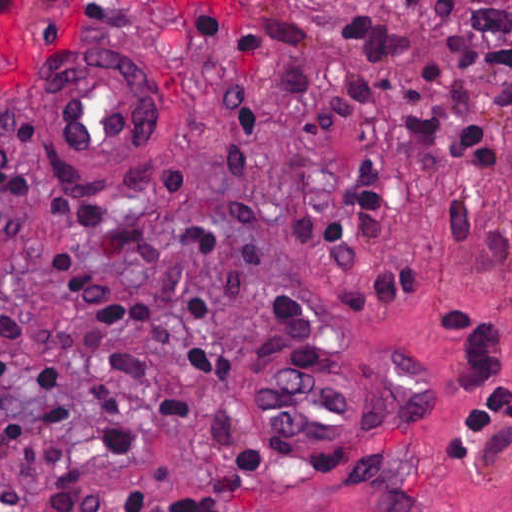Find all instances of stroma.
<instances>
[{
	"label": "stroma",
	"instance_id": "1",
	"mask_svg": "<svg viewBox=\"0 0 512 512\" xmlns=\"http://www.w3.org/2000/svg\"><path fill=\"white\" fill-rule=\"evenodd\" d=\"M343 8L383 15L423 43L497 150L495 169L426 146L390 150L384 231L355 262L309 251L276 221L280 205L288 214H328L334 190L322 176L349 166L348 136L308 141L291 93L297 72L316 80L327 102L356 78L336 32ZM437 13V0H244L243 10L214 13L222 23L179 0H48L0 21V150L19 194L0 229V286L32 307L74 315L51 286L47 255L58 247L74 251L102 289L149 292L143 265L208 286L238 276V397L284 447L240 493L217 496L223 448L207 420L234 399L235 384L191 380L197 409L167 420L153 404L179 367L127 338V349L156 366L142 390L119 382L137 448L106 460L93 416L72 413L88 483L143 488L136 512H167L184 497L230 512H512V419L479 457L449 459L442 444L446 426L467 411L454 384L464 346L440 318L461 308L496 316L509 309L504 269L473 252L490 233L512 242V132L492 81L454 65ZM459 26L512 46V0H470ZM124 41L139 48L134 65L155 94L157 152L119 190L76 191L52 175L44 152L52 64L77 46ZM454 200L472 212L471 253L458 256L446 225ZM183 226L240 229V257L183 250ZM391 265L435 275L404 305H390L371 290ZM346 284L365 292L367 320L344 329ZM270 285L304 301L316 330ZM0 484L15 488L22 512H58L38 502L1 441Z\"/></svg>",
	"mask_w": 512,
	"mask_h": 512
}]
</instances>
